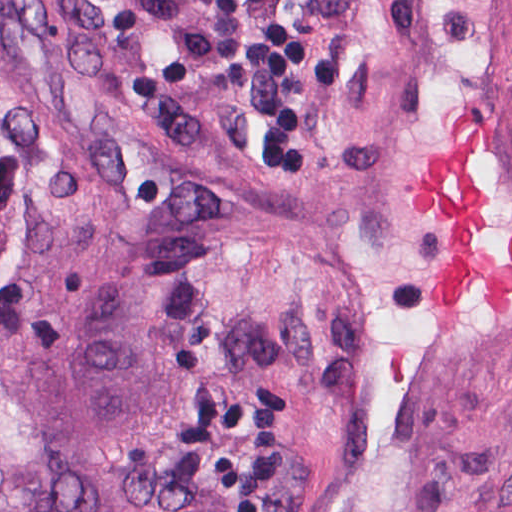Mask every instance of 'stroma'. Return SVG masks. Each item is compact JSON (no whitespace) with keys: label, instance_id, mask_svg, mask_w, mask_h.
<instances>
[{"label":"stroma","instance_id":"stroma-1","mask_svg":"<svg viewBox=\"0 0 512 512\" xmlns=\"http://www.w3.org/2000/svg\"><path fill=\"white\" fill-rule=\"evenodd\" d=\"M3 2L132 111L210 226L245 386L237 512H512V314L471 285L434 302L449 225L407 193L476 109V238L505 264L512 0H340L312 124L275 163L249 128L266 0Z\"/></svg>","mask_w":512,"mask_h":512}]
</instances>
